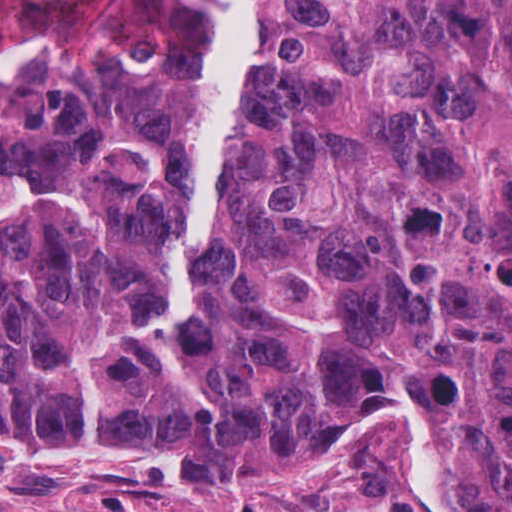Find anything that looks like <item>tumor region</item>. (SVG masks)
Listing matches in <instances>:
<instances>
[{"label": "tumor region", "mask_w": 512, "mask_h": 512, "mask_svg": "<svg viewBox=\"0 0 512 512\" xmlns=\"http://www.w3.org/2000/svg\"><path fill=\"white\" fill-rule=\"evenodd\" d=\"M219 1L0 0V428L289 482L401 388L512 512V0H251L194 319L141 340Z\"/></svg>", "instance_id": "e687c5a6"}]
</instances>
